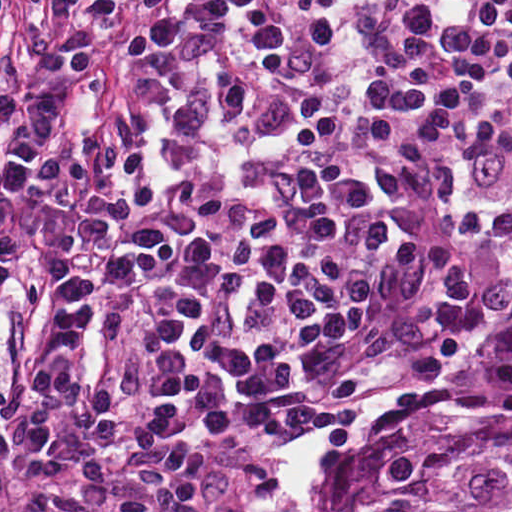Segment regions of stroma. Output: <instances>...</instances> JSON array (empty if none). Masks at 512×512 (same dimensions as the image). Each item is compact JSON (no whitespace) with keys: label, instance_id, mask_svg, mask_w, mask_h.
<instances>
[{"label":"stroma","instance_id":"35a3bbf8","mask_svg":"<svg viewBox=\"0 0 512 512\" xmlns=\"http://www.w3.org/2000/svg\"><path fill=\"white\" fill-rule=\"evenodd\" d=\"M159 0L157 6L161 3ZM147 22L93 60L70 93L65 153L40 210L14 246L0 279V362L24 325L51 294L77 242L100 168L123 141L135 110L138 63ZM512 287V258L476 291L429 362L375 401L326 411L315 436V481L322 512L329 509L331 477L351 429L398 404L426 395L460 370ZM323 412L292 416L222 468L192 482L203 512H295L281 480V462L293 438ZM89 500L85 486L0 485V511L74 506Z\"/></svg>","mask_w":512,"mask_h":512}]
</instances>
